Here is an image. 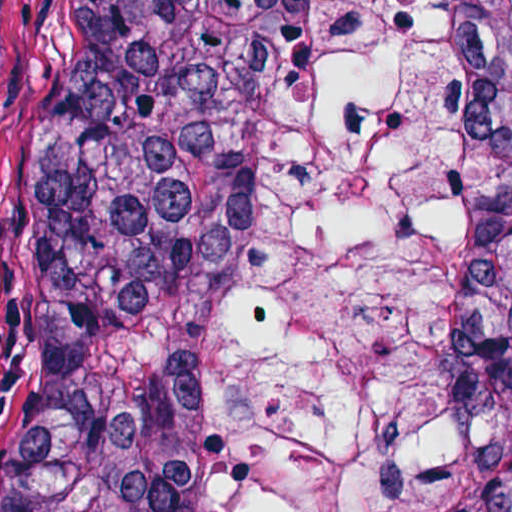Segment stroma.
<instances>
[{
  "instance_id": "obj_1",
  "label": "stroma",
  "mask_w": 512,
  "mask_h": 512,
  "mask_svg": "<svg viewBox=\"0 0 512 512\" xmlns=\"http://www.w3.org/2000/svg\"><path fill=\"white\" fill-rule=\"evenodd\" d=\"M71 46V0H3L0 24V512L37 326L40 173Z\"/></svg>"
}]
</instances>
